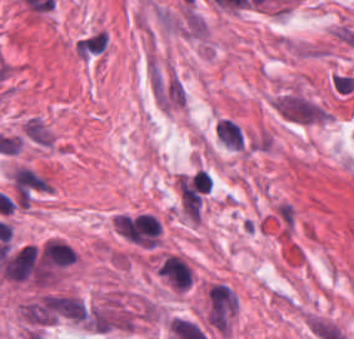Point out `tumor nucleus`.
Listing matches in <instances>:
<instances>
[{
	"label": "tumor nucleus",
	"mask_w": 354,
	"mask_h": 339,
	"mask_svg": "<svg viewBox=\"0 0 354 339\" xmlns=\"http://www.w3.org/2000/svg\"><path fill=\"white\" fill-rule=\"evenodd\" d=\"M24 132L38 143L51 144L53 137L39 116H32L22 125Z\"/></svg>",
	"instance_id": "2f306a5c"
}]
</instances>
